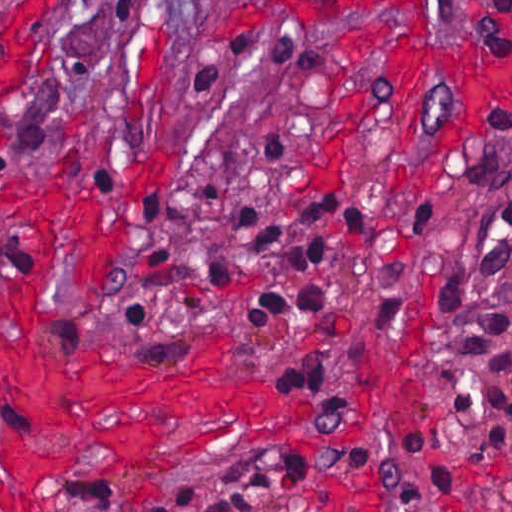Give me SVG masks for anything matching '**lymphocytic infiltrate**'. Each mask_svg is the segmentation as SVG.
<instances>
[{"instance_id":"obj_1","label":"lymphocytic infiltrate","mask_w":512,"mask_h":512,"mask_svg":"<svg viewBox=\"0 0 512 512\" xmlns=\"http://www.w3.org/2000/svg\"><path fill=\"white\" fill-rule=\"evenodd\" d=\"M469 39L478 55L500 59L512 54V0H472L467 14ZM236 63L259 64L285 77H321L332 71L329 51L294 32L225 30L207 37L193 64V83L211 93L224 71ZM502 138L512 140V129ZM218 202V175L203 183L195 200ZM328 222L343 223L365 248L370 239V208L362 199L339 193L257 206L245 199L232 221L234 234L294 270H311L322 258ZM172 249V247H171ZM171 265V250L154 266ZM236 267L227 258L212 262L203 288L228 287ZM183 289V288H177ZM338 294L308 281L295 291L266 284L248 300V327H263L284 314L317 312L333 319ZM154 321V306L143 291L129 300L125 333L143 338ZM471 352L455 366V391L461 411L478 437L500 456L512 440V191L506 214L489 251L484 284L469 325ZM320 349H324L322 346ZM286 383L328 397L330 385L321 361L270 366ZM350 409V406H349ZM512 478V456H501ZM412 473L424 474L426 494L441 512H480L464 490L437 439L418 426L374 470L380 489L400 492ZM324 474L303 457L256 459L224 467L160 496L156 512H285L288 486Z\"/></svg>"}]
</instances>
